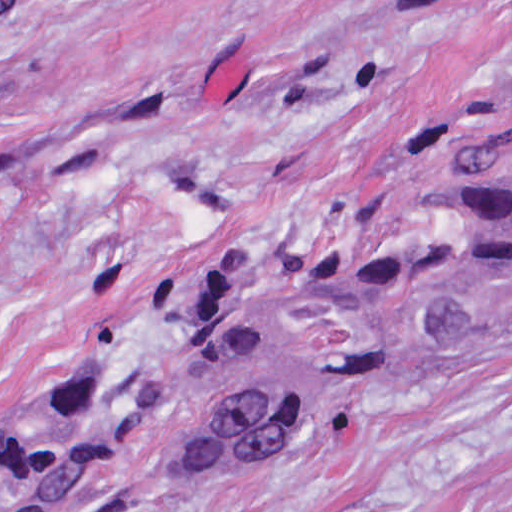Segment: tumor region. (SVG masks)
Here are the masks:
<instances>
[{"mask_svg": "<svg viewBox=\"0 0 512 512\" xmlns=\"http://www.w3.org/2000/svg\"><path fill=\"white\" fill-rule=\"evenodd\" d=\"M511 324L512 114L417 144L272 247L205 265L177 428L193 459L247 472ZM125 458L97 341L6 433L0 512H86Z\"/></svg>", "mask_w": 512, "mask_h": 512, "instance_id": "1", "label": "tumor region"}]
</instances>
